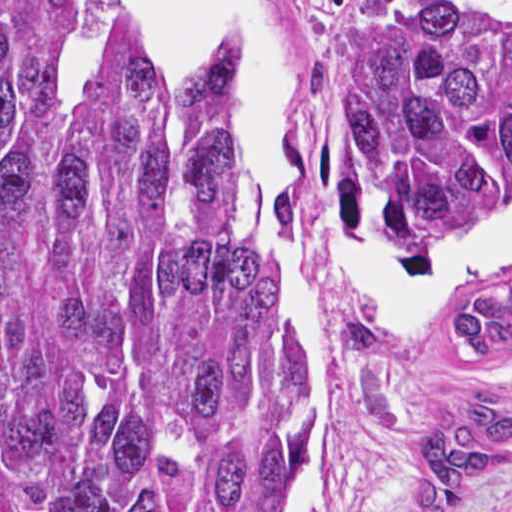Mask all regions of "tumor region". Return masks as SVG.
Returning <instances> with one entry per match:
<instances>
[{
  "label": "tumor region",
  "instance_id": "tumor-region-1",
  "mask_svg": "<svg viewBox=\"0 0 512 512\" xmlns=\"http://www.w3.org/2000/svg\"><path fill=\"white\" fill-rule=\"evenodd\" d=\"M332 107L381 223L512 229V30L400 3L362 18ZM251 164L211 54L113 38L73 93L44 66V0H0V512L277 511L307 354L234 193ZM472 293L451 330L490 357L512 279ZM346 335L377 340L361 317ZM511 452L492 379L437 434L408 512H458Z\"/></svg>",
  "mask_w": 512,
  "mask_h": 512
}]
</instances>
